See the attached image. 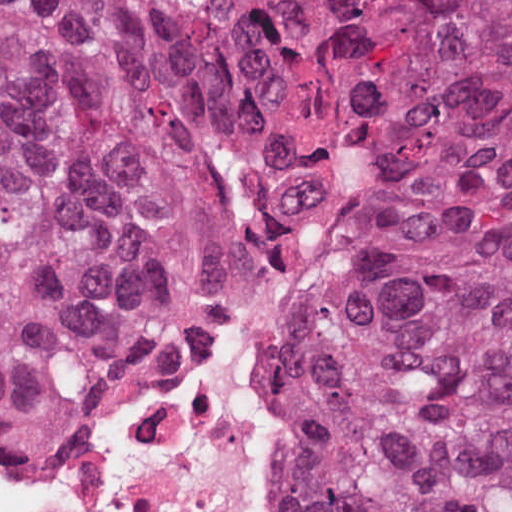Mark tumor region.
Segmentation results:
<instances>
[{
  "instance_id": "e687c5a6",
  "label": "tumor region",
  "mask_w": 512,
  "mask_h": 512,
  "mask_svg": "<svg viewBox=\"0 0 512 512\" xmlns=\"http://www.w3.org/2000/svg\"><path fill=\"white\" fill-rule=\"evenodd\" d=\"M365 148L277 494L512 512V0H0V443L101 434Z\"/></svg>"
}]
</instances>
